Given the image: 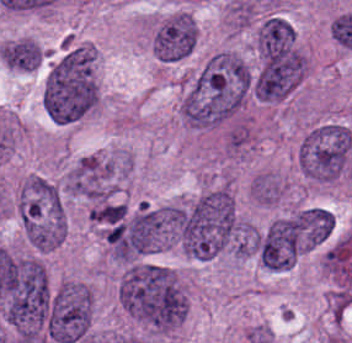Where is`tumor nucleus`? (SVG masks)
Listing matches in <instances>:
<instances>
[{
  "instance_id": "2f306a5c",
  "label": "tumor nucleus",
  "mask_w": 352,
  "mask_h": 343,
  "mask_svg": "<svg viewBox=\"0 0 352 343\" xmlns=\"http://www.w3.org/2000/svg\"><path fill=\"white\" fill-rule=\"evenodd\" d=\"M117 293L126 313L154 330L169 331L184 317L183 291L162 264L127 261Z\"/></svg>"
},
{
  "instance_id": "8643909e",
  "label": "tumor nucleus",
  "mask_w": 352,
  "mask_h": 343,
  "mask_svg": "<svg viewBox=\"0 0 352 343\" xmlns=\"http://www.w3.org/2000/svg\"><path fill=\"white\" fill-rule=\"evenodd\" d=\"M98 98L94 51L72 45L48 72L43 106L52 120L75 121L93 109Z\"/></svg>"
},
{
  "instance_id": "5ab6c2c4",
  "label": "tumor nucleus",
  "mask_w": 352,
  "mask_h": 343,
  "mask_svg": "<svg viewBox=\"0 0 352 343\" xmlns=\"http://www.w3.org/2000/svg\"><path fill=\"white\" fill-rule=\"evenodd\" d=\"M352 153L350 130L337 123L314 126L299 146L301 168L310 178L332 182L340 177Z\"/></svg>"
},
{
  "instance_id": "2cbd58db",
  "label": "tumor nucleus",
  "mask_w": 352,
  "mask_h": 343,
  "mask_svg": "<svg viewBox=\"0 0 352 343\" xmlns=\"http://www.w3.org/2000/svg\"><path fill=\"white\" fill-rule=\"evenodd\" d=\"M93 299L88 287L68 282L51 293L45 328L56 343H75L84 339L91 322Z\"/></svg>"
},
{
  "instance_id": "3d1891a8",
  "label": "tumor nucleus",
  "mask_w": 352,
  "mask_h": 343,
  "mask_svg": "<svg viewBox=\"0 0 352 343\" xmlns=\"http://www.w3.org/2000/svg\"><path fill=\"white\" fill-rule=\"evenodd\" d=\"M197 42L196 25L189 15L166 21L153 36V50L162 62H178L191 54Z\"/></svg>"
},
{
  "instance_id": "2083b535",
  "label": "tumor nucleus",
  "mask_w": 352,
  "mask_h": 343,
  "mask_svg": "<svg viewBox=\"0 0 352 343\" xmlns=\"http://www.w3.org/2000/svg\"><path fill=\"white\" fill-rule=\"evenodd\" d=\"M259 259L266 267L284 268L296 258L290 216L274 219L256 236Z\"/></svg>"
},
{
  "instance_id": "8087334f",
  "label": "tumor nucleus",
  "mask_w": 352,
  "mask_h": 343,
  "mask_svg": "<svg viewBox=\"0 0 352 343\" xmlns=\"http://www.w3.org/2000/svg\"><path fill=\"white\" fill-rule=\"evenodd\" d=\"M294 42L291 25L283 18L269 15L258 29L256 45L261 63Z\"/></svg>"
},
{
  "instance_id": "c2bd9aea",
  "label": "tumor nucleus",
  "mask_w": 352,
  "mask_h": 343,
  "mask_svg": "<svg viewBox=\"0 0 352 343\" xmlns=\"http://www.w3.org/2000/svg\"><path fill=\"white\" fill-rule=\"evenodd\" d=\"M0 54L5 63L22 71H32L42 58L37 42L25 37L1 46Z\"/></svg>"
},
{
  "instance_id": "feef74b5",
  "label": "tumor nucleus",
  "mask_w": 352,
  "mask_h": 343,
  "mask_svg": "<svg viewBox=\"0 0 352 343\" xmlns=\"http://www.w3.org/2000/svg\"><path fill=\"white\" fill-rule=\"evenodd\" d=\"M231 12L239 24H248L254 15V7L251 2L241 1L232 5Z\"/></svg>"
}]
</instances>
